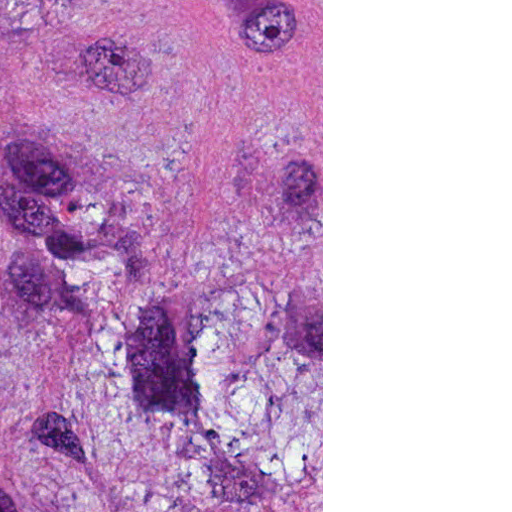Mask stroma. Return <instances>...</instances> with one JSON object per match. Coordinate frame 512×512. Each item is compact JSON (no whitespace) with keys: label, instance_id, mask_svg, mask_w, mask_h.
<instances>
[{"label":"stroma","instance_id":"1","mask_svg":"<svg viewBox=\"0 0 512 512\" xmlns=\"http://www.w3.org/2000/svg\"><path fill=\"white\" fill-rule=\"evenodd\" d=\"M161 512H323V0H161Z\"/></svg>","mask_w":512,"mask_h":512}]
</instances>
